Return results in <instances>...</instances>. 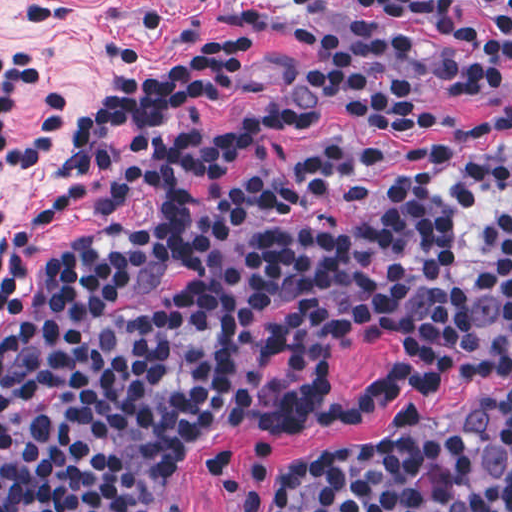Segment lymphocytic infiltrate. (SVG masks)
<instances>
[{
	"label": "lymphocytic infiltrate",
	"mask_w": 512,
	"mask_h": 512,
	"mask_svg": "<svg viewBox=\"0 0 512 512\" xmlns=\"http://www.w3.org/2000/svg\"><path fill=\"white\" fill-rule=\"evenodd\" d=\"M299 81L362 124L442 132L399 75L436 47L462 94L512 80V1L460 18L348 3L333 67H316V31L277 28ZM261 44L240 41L142 69L69 131L72 98L38 86L42 55L0 51V171L71 139L75 150L35 223L133 205L130 130L149 158L156 216L55 249L16 308L29 247L0 260V512H181L171 454L222 425L290 431L354 423L421 388L512 369V113L422 145L349 136L311 143L282 168L236 175L245 157L289 142L305 104L230 125L194 116L234 99ZM384 332L396 360L372 387L340 396L331 359ZM213 484L241 512H512V390L436 425L404 416L385 439L327 457L261 443L250 470L224 448Z\"/></svg>",
	"instance_id": "obj_1"
}]
</instances>
